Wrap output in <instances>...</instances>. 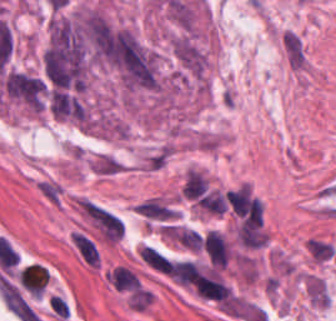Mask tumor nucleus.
<instances>
[{"mask_svg":"<svg viewBox=\"0 0 336 321\" xmlns=\"http://www.w3.org/2000/svg\"><path fill=\"white\" fill-rule=\"evenodd\" d=\"M0 86L9 101L28 111L41 112L42 79L40 75L8 69L1 75Z\"/></svg>","mask_w":336,"mask_h":321,"instance_id":"obj_2","label":"tumor nucleus"},{"mask_svg":"<svg viewBox=\"0 0 336 321\" xmlns=\"http://www.w3.org/2000/svg\"><path fill=\"white\" fill-rule=\"evenodd\" d=\"M110 61L123 86L130 90H156L159 85L155 53L128 30L107 34Z\"/></svg>","mask_w":336,"mask_h":321,"instance_id":"obj_1","label":"tumor nucleus"}]
</instances>
